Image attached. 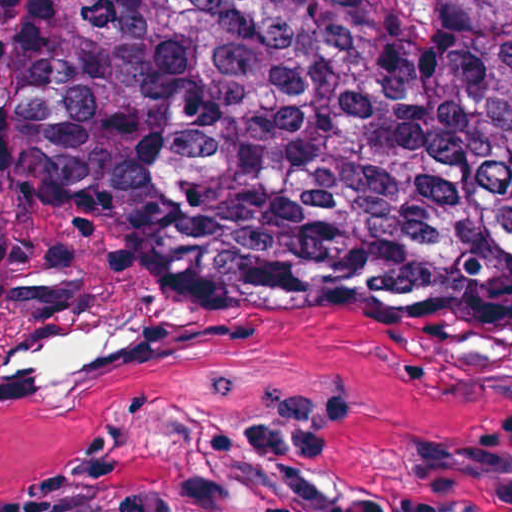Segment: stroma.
Instances as JSON below:
<instances>
[{"mask_svg":"<svg viewBox=\"0 0 512 512\" xmlns=\"http://www.w3.org/2000/svg\"><path fill=\"white\" fill-rule=\"evenodd\" d=\"M150 319L94 373L0 369V512H512V249L349 222L0 223V347Z\"/></svg>","mask_w":512,"mask_h":512,"instance_id":"35a3bbf8","label":"stroma"}]
</instances>
